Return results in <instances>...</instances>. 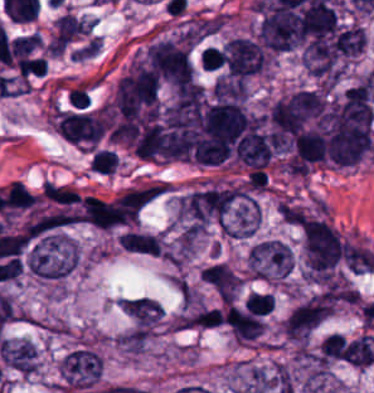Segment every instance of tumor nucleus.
Listing matches in <instances>:
<instances>
[{"label":"tumor nucleus","instance_id":"tumor-nucleus-1","mask_svg":"<svg viewBox=\"0 0 374 393\" xmlns=\"http://www.w3.org/2000/svg\"><path fill=\"white\" fill-rule=\"evenodd\" d=\"M24 263L30 274L49 281L67 276L77 266L78 254L68 236L54 231L27 244Z\"/></svg>","mask_w":374,"mask_h":393},{"label":"tumor nucleus","instance_id":"tumor-nucleus-2","mask_svg":"<svg viewBox=\"0 0 374 393\" xmlns=\"http://www.w3.org/2000/svg\"><path fill=\"white\" fill-rule=\"evenodd\" d=\"M303 253L307 274L317 278L339 265L344 244L328 221L308 219L303 227Z\"/></svg>","mask_w":374,"mask_h":393},{"label":"tumor nucleus","instance_id":"tumor-nucleus-3","mask_svg":"<svg viewBox=\"0 0 374 393\" xmlns=\"http://www.w3.org/2000/svg\"><path fill=\"white\" fill-rule=\"evenodd\" d=\"M331 309L332 304L317 292L297 301L282 320V338L302 346L331 315Z\"/></svg>","mask_w":374,"mask_h":393},{"label":"tumor nucleus","instance_id":"tumor-nucleus-4","mask_svg":"<svg viewBox=\"0 0 374 393\" xmlns=\"http://www.w3.org/2000/svg\"><path fill=\"white\" fill-rule=\"evenodd\" d=\"M144 66L154 77L178 86L193 77L187 48L168 38L149 44Z\"/></svg>","mask_w":374,"mask_h":393},{"label":"tumor nucleus","instance_id":"tumor-nucleus-5","mask_svg":"<svg viewBox=\"0 0 374 393\" xmlns=\"http://www.w3.org/2000/svg\"><path fill=\"white\" fill-rule=\"evenodd\" d=\"M246 261L251 278L261 280L285 278L294 264L291 250L278 240L255 244Z\"/></svg>","mask_w":374,"mask_h":393},{"label":"tumor nucleus","instance_id":"tumor-nucleus-6","mask_svg":"<svg viewBox=\"0 0 374 393\" xmlns=\"http://www.w3.org/2000/svg\"><path fill=\"white\" fill-rule=\"evenodd\" d=\"M0 349L8 369L28 377L38 371L35 344L29 338H3Z\"/></svg>","mask_w":374,"mask_h":393},{"label":"tumor nucleus","instance_id":"tumor-nucleus-7","mask_svg":"<svg viewBox=\"0 0 374 393\" xmlns=\"http://www.w3.org/2000/svg\"><path fill=\"white\" fill-rule=\"evenodd\" d=\"M120 249L135 255L159 256L164 245L161 237L148 231L125 229L116 237Z\"/></svg>","mask_w":374,"mask_h":393},{"label":"tumor nucleus","instance_id":"tumor-nucleus-8","mask_svg":"<svg viewBox=\"0 0 374 393\" xmlns=\"http://www.w3.org/2000/svg\"><path fill=\"white\" fill-rule=\"evenodd\" d=\"M212 94L216 102H243L247 95L246 81L241 78H217Z\"/></svg>","mask_w":374,"mask_h":393},{"label":"tumor nucleus","instance_id":"tumor-nucleus-9","mask_svg":"<svg viewBox=\"0 0 374 393\" xmlns=\"http://www.w3.org/2000/svg\"><path fill=\"white\" fill-rule=\"evenodd\" d=\"M223 51L218 46H205L198 53V61L203 71H215L224 62Z\"/></svg>","mask_w":374,"mask_h":393}]
</instances>
